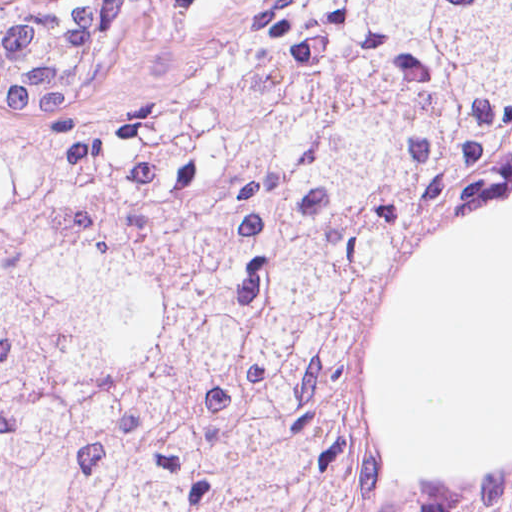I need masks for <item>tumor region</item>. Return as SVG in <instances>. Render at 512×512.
<instances>
[{
	"mask_svg": "<svg viewBox=\"0 0 512 512\" xmlns=\"http://www.w3.org/2000/svg\"><path fill=\"white\" fill-rule=\"evenodd\" d=\"M93 0H0V512H512L352 464L341 328L512 177V0H256L103 105Z\"/></svg>",
	"mask_w": 512,
	"mask_h": 512,
	"instance_id": "e687c5a6",
	"label": "tumor region"
}]
</instances>
